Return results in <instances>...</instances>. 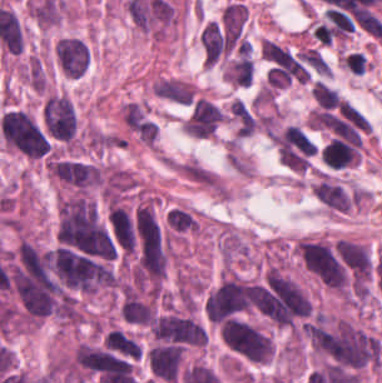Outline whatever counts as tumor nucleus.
I'll use <instances>...</instances> for the list:
<instances>
[{"label": "tumor nucleus", "mask_w": 382, "mask_h": 383, "mask_svg": "<svg viewBox=\"0 0 382 383\" xmlns=\"http://www.w3.org/2000/svg\"><path fill=\"white\" fill-rule=\"evenodd\" d=\"M183 351L180 346L158 343L148 350L147 362L153 381L178 382Z\"/></svg>", "instance_id": "tumor-nucleus-7"}, {"label": "tumor nucleus", "mask_w": 382, "mask_h": 383, "mask_svg": "<svg viewBox=\"0 0 382 383\" xmlns=\"http://www.w3.org/2000/svg\"><path fill=\"white\" fill-rule=\"evenodd\" d=\"M59 239L73 249L98 258H114L115 242L95 204L86 197L59 203Z\"/></svg>", "instance_id": "tumor-nucleus-1"}, {"label": "tumor nucleus", "mask_w": 382, "mask_h": 383, "mask_svg": "<svg viewBox=\"0 0 382 383\" xmlns=\"http://www.w3.org/2000/svg\"><path fill=\"white\" fill-rule=\"evenodd\" d=\"M107 346L130 354L132 356H138L140 354L139 345L134 342L128 335L123 331L112 329L109 331L105 340Z\"/></svg>", "instance_id": "tumor-nucleus-12"}, {"label": "tumor nucleus", "mask_w": 382, "mask_h": 383, "mask_svg": "<svg viewBox=\"0 0 382 383\" xmlns=\"http://www.w3.org/2000/svg\"><path fill=\"white\" fill-rule=\"evenodd\" d=\"M151 330L158 341L204 344L205 333L198 322L188 316L168 313L151 321Z\"/></svg>", "instance_id": "tumor-nucleus-3"}, {"label": "tumor nucleus", "mask_w": 382, "mask_h": 383, "mask_svg": "<svg viewBox=\"0 0 382 383\" xmlns=\"http://www.w3.org/2000/svg\"><path fill=\"white\" fill-rule=\"evenodd\" d=\"M50 167L64 185L82 192L99 182L98 168L91 162L60 157L53 158Z\"/></svg>", "instance_id": "tumor-nucleus-5"}, {"label": "tumor nucleus", "mask_w": 382, "mask_h": 383, "mask_svg": "<svg viewBox=\"0 0 382 383\" xmlns=\"http://www.w3.org/2000/svg\"><path fill=\"white\" fill-rule=\"evenodd\" d=\"M302 61L318 74H328L329 67L322 54L313 47H306L295 53Z\"/></svg>", "instance_id": "tumor-nucleus-14"}, {"label": "tumor nucleus", "mask_w": 382, "mask_h": 383, "mask_svg": "<svg viewBox=\"0 0 382 383\" xmlns=\"http://www.w3.org/2000/svg\"><path fill=\"white\" fill-rule=\"evenodd\" d=\"M229 110L237 136H248L257 126L243 100L237 98Z\"/></svg>", "instance_id": "tumor-nucleus-10"}, {"label": "tumor nucleus", "mask_w": 382, "mask_h": 383, "mask_svg": "<svg viewBox=\"0 0 382 383\" xmlns=\"http://www.w3.org/2000/svg\"><path fill=\"white\" fill-rule=\"evenodd\" d=\"M1 133L7 144L30 156H40L46 142L29 114L9 109L2 115Z\"/></svg>", "instance_id": "tumor-nucleus-2"}, {"label": "tumor nucleus", "mask_w": 382, "mask_h": 383, "mask_svg": "<svg viewBox=\"0 0 382 383\" xmlns=\"http://www.w3.org/2000/svg\"><path fill=\"white\" fill-rule=\"evenodd\" d=\"M166 224L171 232L180 233L195 228V218L179 207H172L167 211Z\"/></svg>", "instance_id": "tumor-nucleus-11"}, {"label": "tumor nucleus", "mask_w": 382, "mask_h": 383, "mask_svg": "<svg viewBox=\"0 0 382 383\" xmlns=\"http://www.w3.org/2000/svg\"><path fill=\"white\" fill-rule=\"evenodd\" d=\"M55 61L63 74L79 78L88 68V45L83 39L65 35L55 43Z\"/></svg>", "instance_id": "tumor-nucleus-6"}, {"label": "tumor nucleus", "mask_w": 382, "mask_h": 383, "mask_svg": "<svg viewBox=\"0 0 382 383\" xmlns=\"http://www.w3.org/2000/svg\"><path fill=\"white\" fill-rule=\"evenodd\" d=\"M311 95L320 108H333L338 103L337 92L318 79L311 86Z\"/></svg>", "instance_id": "tumor-nucleus-13"}, {"label": "tumor nucleus", "mask_w": 382, "mask_h": 383, "mask_svg": "<svg viewBox=\"0 0 382 383\" xmlns=\"http://www.w3.org/2000/svg\"><path fill=\"white\" fill-rule=\"evenodd\" d=\"M153 311L152 304L126 292L119 313L126 322L150 323Z\"/></svg>", "instance_id": "tumor-nucleus-9"}, {"label": "tumor nucleus", "mask_w": 382, "mask_h": 383, "mask_svg": "<svg viewBox=\"0 0 382 383\" xmlns=\"http://www.w3.org/2000/svg\"><path fill=\"white\" fill-rule=\"evenodd\" d=\"M260 49L265 58L281 64L291 56L287 48L264 38L260 41Z\"/></svg>", "instance_id": "tumor-nucleus-15"}, {"label": "tumor nucleus", "mask_w": 382, "mask_h": 383, "mask_svg": "<svg viewBox=\"0 0 382 383\" xmlns=\"http://www.w3.org/2000/svg\"><path fill=\"white\" fill-rule=\"evenodd\" d=\"M153 91L159 98L179 104H189L194 93L187 82L178 78H158L154 82Z\"/></svg>", "instance_id": "tumor-nucleus-8"}, {"label": "tumor nucleus", "mask_w": 382, "mask_h": 383, "mask_svg": "<svg viewBox=\"0 0 382 383\" xmlns=\"http://www.w3.org/2000/svg\"><path fill=\"white\" fill-rule=\"evenodd\" d=\"M221 324L225 326L230 332H232L236 337H238L242 342H244L255 353H257L262 359H264L262 355L252 346V344L243 336V334L233 325V323L228 318H224Z\"/></svg>", "instance_id": "tumor-nucleus-16"}, {"label": "tumor nucleus", "mask_w": 382, "mask_h": 383, "mask_svg": "<svg viewBox=\"0 0 382 383\" xmlns=\"http://www.w3.org/2000/svg\"><path fill=\"white\" fill-rule=\"evenodd\" d=\"M43 119L55 138L70 140L75 133L76 117L68 95L50 94L45 99Z\"/></svg>", "instance_id": "tumor-nucleus-4"}]
</instances>
